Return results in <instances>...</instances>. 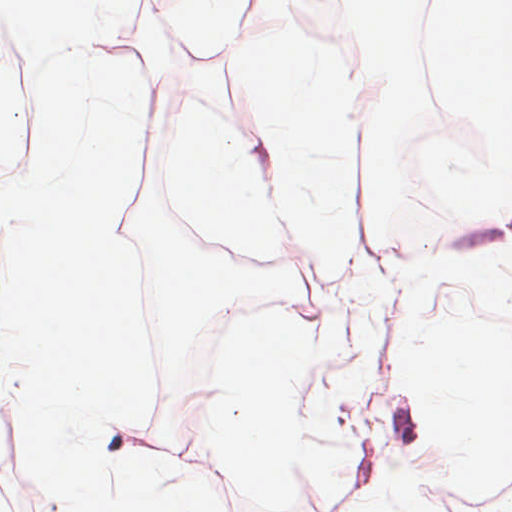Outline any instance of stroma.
Masks as SVG:
<instances>
[{
	"instance_id": "stroma-1",
	"label": "stroma",
	"mask_w": 512,
	"mask_h": 512,
	"mask_svg": "<svg viewBox=\"0 0 512 512\" xmlns=\"http://www.w3.org/2000/svg\"><path fill=\"white\" fill-rule=\"evenodd\" d=\"M437 3L411 0L365 67L387 97L377 161L389 123L409 114L420 132L437 122L428 71ZM290 30L340 45L323 0H253L237 30L220 40L192 35L173 0H136L126 39L111 61L136 60L147 80L148 161L171 165L183 121L201 111L245 136L264 186L279 188L284 169L252 80L251 53ZM16 55H25L19 46ZM461 141L470 156L512 184V172ZM493 235L512 238V186Z\"/></svg>"
}]
</instances>
